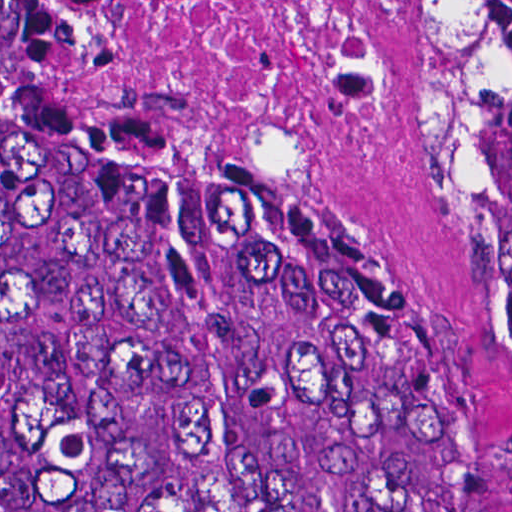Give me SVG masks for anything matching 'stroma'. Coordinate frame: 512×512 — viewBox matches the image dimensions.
<instances>
[{
  "instance_id": "35a3bbf8",
  "label": "stroma",
  "mask_w": 512,
  "mask_h": 512,
  "mask_svg": "<svg viewBox=\"0 0 512 512\" xmlns=\"http://www.w3.org/2000/svg\"><path fill=\"white\" fill-rule=\"evenodd\" d=\"M304 166L424 366L485 512H512V309L489 195H450L421 167L413 100L380 151Z\"/></svg>"
}]
</instances>
